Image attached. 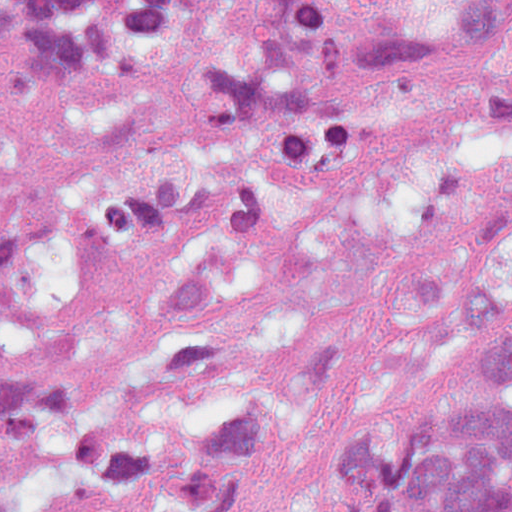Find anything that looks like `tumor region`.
Here are the masks:
<instances>
[{
  "instance_id": "obj_1",
  "label": "tumor region",
  "mask_w": 512,
  "mask_h": 512,
  "mask_svg": "<svg viewBox=\"0 0 512 512\" xmlns=\"http://www.w3.org/2000/svg\"><path fill=\"white\" fill-rule=\"evenodd\" d=\"M0 26L19 99L56 75L140 91L68 130L71 212L107 246L170 245L229 184L325 181L389 82L512 145V0H0ZM33 238L0 221V260ZM486 339L492 398L375 414L331 512H512V276L348 234L207 250L80 383L0 369V512H250L340 396L440 378Z\"/></svg>"
}]
</instances>
